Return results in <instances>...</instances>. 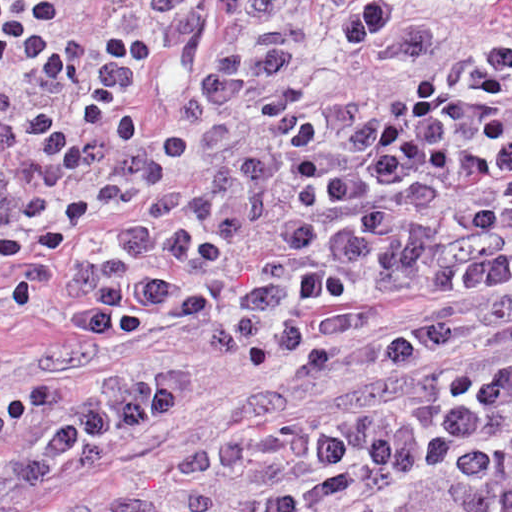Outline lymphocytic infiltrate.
<instances>
[{"instance_id": "f902f5d3", "label": "lymphocytic infiltrate", "mask_w": 512, "mask_h": 512, "mask_svg": "<svg viewBox=\"0 0 512 512\" xmlns=\"http://www.w3.org/2000/svg\"><path fill=\"white\" fill-rule=\"evenodd\" d=\"M59 0H0V72L31 76L65 104L84 136L107 148H135L154 138L139 103L143 70L157 55L154 37L113 28L97 40L59 43ZM49 109L0 122V149L52 123ZM72 145L37 140L27 158L74 168Z\"/></svg>"}]
</instances>
